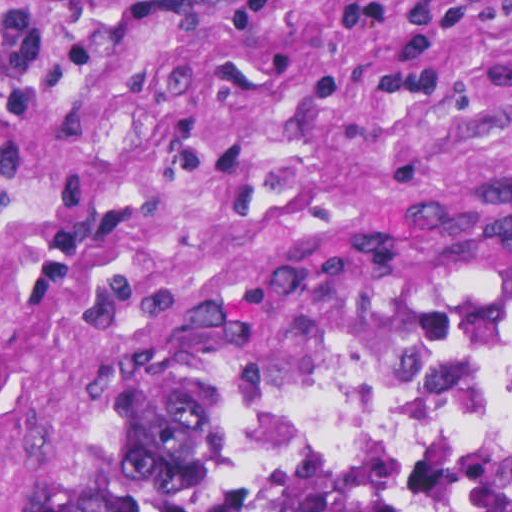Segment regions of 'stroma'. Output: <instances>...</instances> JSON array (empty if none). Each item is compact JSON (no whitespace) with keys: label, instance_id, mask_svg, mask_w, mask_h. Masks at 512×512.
Masks as SVG:
<instances>
[{"label":"stroma","instance_id":"1","mask_svg":"<svg viewBox=\"0 0 512 512\" xmlns=\"http://www.w3.org/2000/svg\"><path fill=\"white\" fill-rule=\"evenodd\" d=\"M375 240L512 243V0H0V512Z\"/></svg>","mask_w":512,"mask_h":512}]
</instances>
